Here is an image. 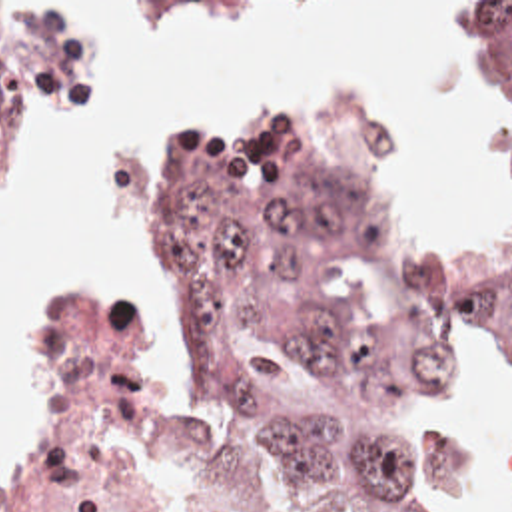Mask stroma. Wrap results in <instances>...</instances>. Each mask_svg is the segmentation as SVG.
Wrapping results in <instances>:
<instances>
[{
	"mask_svg": "<svg viewBox=\"0 0 512 512\" xmlns=\"http://www.w3.org/2000/svg\"><path fill=\"white\" fill-rule=\"evenodd\" d=\"M0 2H49L55 6H85L123 18V118L105 134L73 146L39 166L19 188L17 212L9 234L31 200L59 180L75 174L109 140L125 134L133 102V76L139 62V12L161 2H253L277 14H440L454 18L462 54L474 78L480 76L464 40V2L512 0H0ZM494 96V92H492ZM251 100H331L356 114V190L372 210L406 244L432 252H468L494 242L512 226V140L500 112V184L478 224L460 230H428L400 210L388 182L384 158L376 146L374 124L366 108L341 92H217L195 98L169 118L147 146L137 182V232L119 266H93L79 270L53 291L41 311V409L37 421L0 479V497L35 485L55 449L59 427V341L65 313L97 295H131L123 299L145 313V283L151 262V228L161 204L167 166L173 150L197 126L215 120ZM496 100V96H494ZM498 104V102H496ZM7 234V236H9ZM7 240V238H5ZM209 409L213 431V479L223 512H277V493L257 463Z\"/></svg>",
	"mask_w": 512,
	"mask_h": 512,
	"instance_id": "35a3bbf8",
	"label": "stroma"
}]
</instances>
